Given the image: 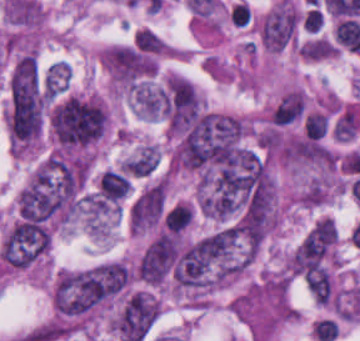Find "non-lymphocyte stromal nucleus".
Instances as JSON below:
<instances>
[{
	"label": "non-lymphocyte stromal nucleus",
	"mask_w": 360,
	"mask_h": 341,
	"mask_svg": "<svg viewBox=\"0 0 360 341\" xmlns=\"http://www.w3.org/2000/svg\"><path fill=\"white\" fill-rule=\"evenodd\" d=\"M298 17L290 2H283L263 17L260 41L268 50H282L296 34Z\"/></svg>",
	"instance_id": "non-lymphocyte-stromal-nucleus-1"
}]
</instances>
